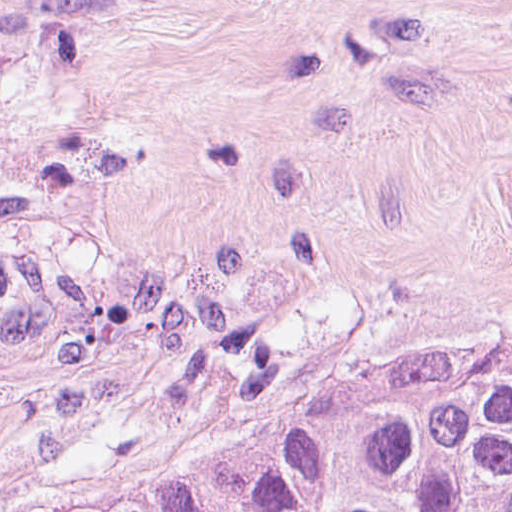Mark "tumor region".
<instances>
[{"instance_id": "obj_1", "label": "tumor region", "mask_w": 512, "mask_h": 512, "mask_svg": "<svg viewBox=\"0 0 512 512\" xmlns=\"http://www.w3.org/2000/svg\"><path fill=\"white\" fill-rule=\"evenodd\" d=\"M76 512H512V361H368L246 442Z\"/></svg>"}]
</instances>
